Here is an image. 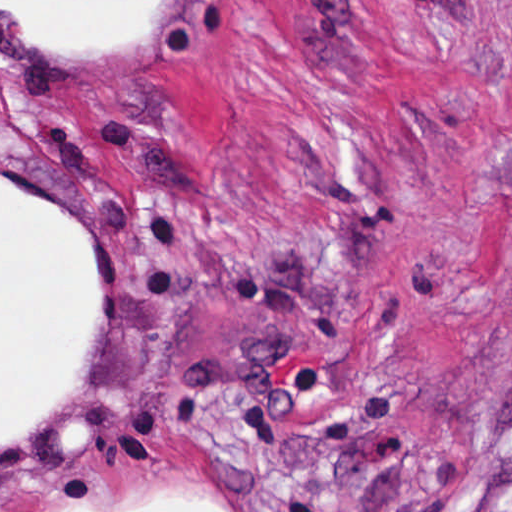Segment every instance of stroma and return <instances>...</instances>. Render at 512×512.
<instances>
[{
    "mask_svg": "<svg viewBox=\"0 0 512 512\" xmlns=\"http://www.w3.org/2000/svg\"><path fill=\"white\" fill-rule=\"evenodd\" d=\"M1 180L53 203L84 348L1 450ZM512 0H0V512H503ZM177 506V505H174Z\"/></svg>",
    "mask_w": 512,
    "mask_h": 512,
    "instance_id": "1",
    "label": "stroma"
}]
</instances>
